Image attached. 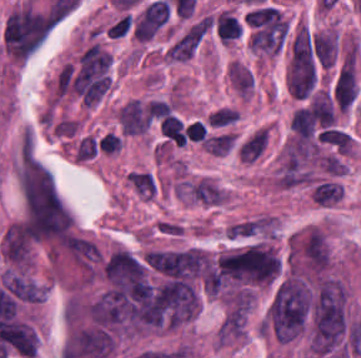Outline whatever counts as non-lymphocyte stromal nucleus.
I'll list each match as a JSON object with an SVG mask.
<instances>
[{
    "label": "non-lymphocyte stromal nucleus",
    "mask_w": 361,
    "mask_h": 358,
    "mask_svg": "<svg viewBox=\"0 0 361 358\" xmlns=\"http://www.w3.org/2000/svg\"><path fill=\"white\" fill-rule=\"evenodd\" d=\"M342 189L333 180H319L312 185L311 197L313 202L321 206H329L341 200Z\"/></svg>",
    "instance_id": "obj_1"
},
{
    "label": "non-lymphocyte stromal nucleus",
    "mask_w": 361,
    "mask_h": 358,
    "mask_svg": "<svg viewBox=\"0 0 361 358\" xmlns=\"http://www.w3.org/2000/svg\"><path fill=\"white\" fill-rule=\"evenodd\" d=\"M267 143V133L262 128L254 132L238 148L241 161H251L263 152Z\"/></svg>",
    "instance_id": "obj_2"
}]
</instances>
